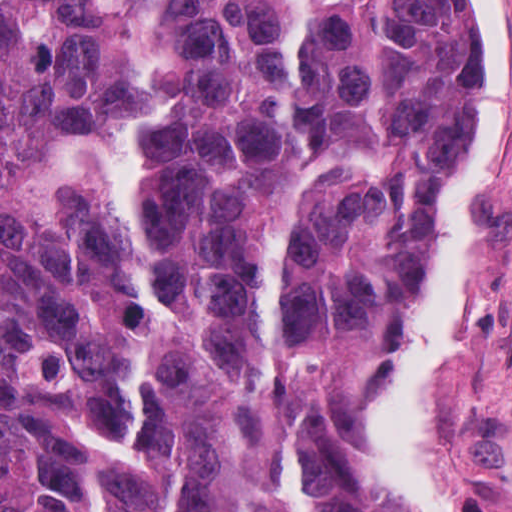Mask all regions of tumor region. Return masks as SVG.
I'll return each mask as SVG.
<instances>
[{
	"label": "tumor region",
	"instance_id": "1",
	"mask_svg": "<svg viewBox=\"0 0 512 512\" xmlns=\"http://www.w3.org/2000/svg\"><path fill=\"white\" fill-rule=\"evenodd\" d=\"M131 2L172 67L140 231L168 314L77 168L137 109L129 43L100 0H0V512H371L347 421L472 168L466 2Z\"/></svg>",
	"mask_w": 512,
	"mask_h": 512
}]
</instances>
